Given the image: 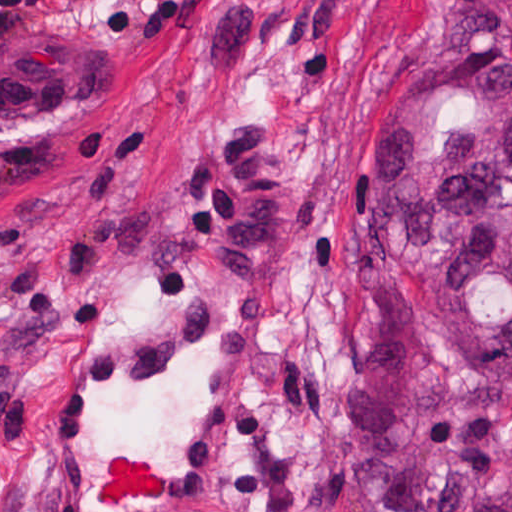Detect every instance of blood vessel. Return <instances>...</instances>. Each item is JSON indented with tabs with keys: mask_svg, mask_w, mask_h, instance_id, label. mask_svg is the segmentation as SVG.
<instances>
[{
	"mask_svg": "<svg viewBox=\"0 0 512 512\" xmlns=\"http://www.w3.org/2000/svg\"><path fill=\"white\" fill-rule=\"evenodd\" d=\"M276 357L250 305L165 312L44 388L46 512H200Z\"/></svg>",
	"mask_w": 512,
	"mask_h": 512,
	"instance_id": "8fb6f2fc",
	"label": "blood vessel"
}]
</instances>
